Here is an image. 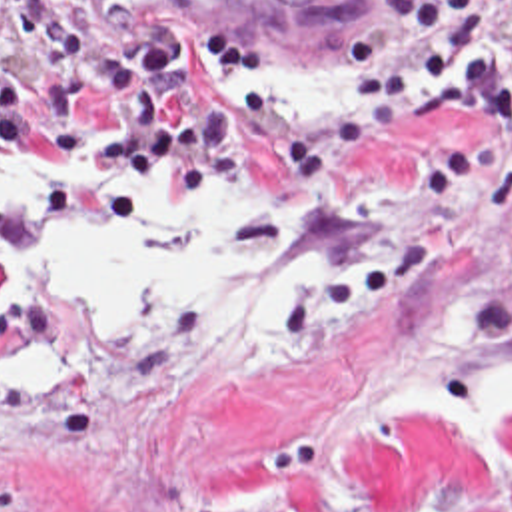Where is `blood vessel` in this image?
Returning <instances> with one entry per match:
<instances>
[{"instance_id":"obj_1","label":"blood vessel","mask_w":512,"mask_h":512,"mask_svg":"<svg viewBox=\"0 0 512 512\" xmlns=\"http://www.w3.org/2000/svg\"><path fill=\"white\" fill-rule=\"evenodd\" d=\"M394 0H44L62 41L226 69L350 35Z\"/></svg>"}]
</instances>
